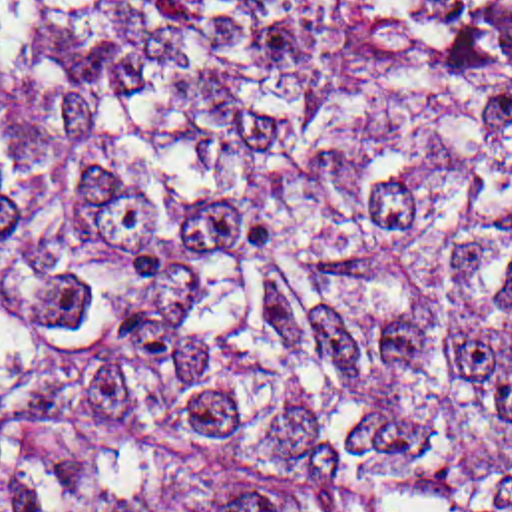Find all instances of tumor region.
Here are the masks:
<instances>
[{"label": "tumor region", "instance_id": "obj_1", "mask_svg": "<svg viewBox=\"0 0 512 512\" xmlns=\"http://www.w3.org/2000/svg\"><path fill=\"white\" fill-rule=\"evenodd\" d=\"M0 512H512V0H0Z\"/></svg>", "mask_w": 512, "mask_h": 512}]
</instances>
